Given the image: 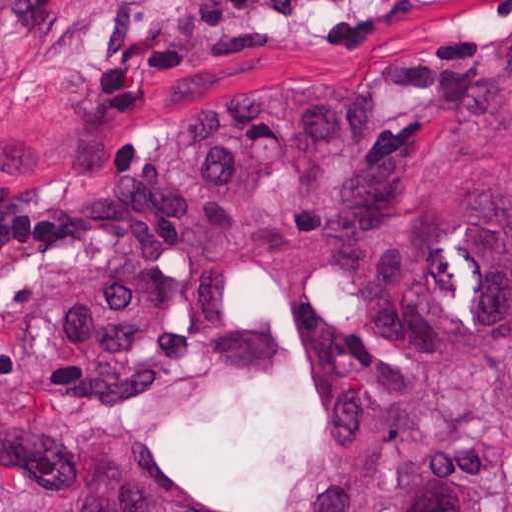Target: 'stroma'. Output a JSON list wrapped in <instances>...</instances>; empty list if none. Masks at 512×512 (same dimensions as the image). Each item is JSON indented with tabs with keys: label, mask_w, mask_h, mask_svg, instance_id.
Instances as JSON below:
<instances>
[{
	"label": "stroma",
	"mask_w": 512,
	"mask_h": 512,
	"mask_svg": "<svg viewBox=\"0 0 512 512\" xmlns=\"http://www.w3.org/2000/svg\"><path fill=\"white\" fill-rule=\"evenodd\" d=\"M508 2L337 0L229 19L202 0H0V181L117 171L181 122L281 85H317L350 113L382 118L394 98L386 78L417 44L494 39ZM231 311L270 327L277 360L226 393L213 423L150 432L204 496L232 512H272L319 423L320 366L265 269L240 267ZM44 488L0 471V495Z\"/></svg>",
	"instance_id": "35a3bbf8"
}]
</instances>
